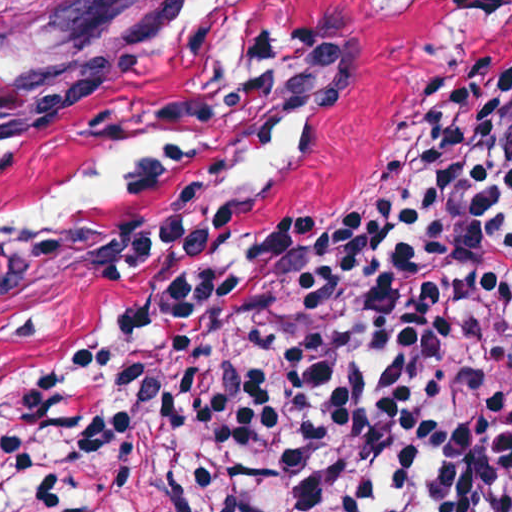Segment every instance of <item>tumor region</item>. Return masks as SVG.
<instances>
[{"mask_svg":"<svg viewBox=\"0 0 512 512\" xmlns=\"http://www.w3.org/2000/svg\"><path fill=\"white\" fill-rule=\"evenodd\" d=\"M377 170L350 193L361 189ZM313 213H307L309 215ZM125 414L140 467L156 512H180L181 480L169 401L154 393H96L77 398L39 432L19 431L16 409L0 427V491L29 473L68 432L95 419ZM512 512V511H511Z\"/></svg>","mask_w":512,"mask_h":512,"instance_id":"1","label":"tumor region"}]
</instances>
